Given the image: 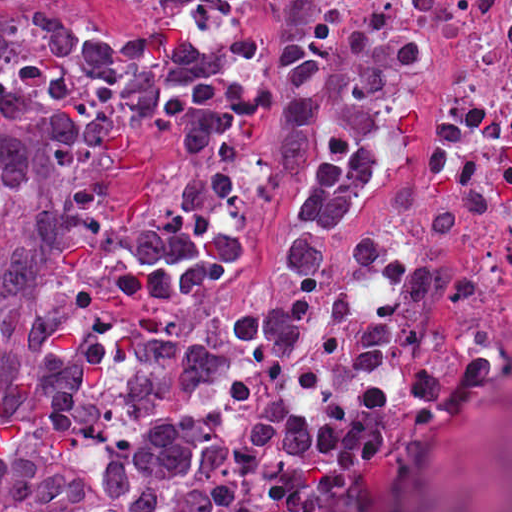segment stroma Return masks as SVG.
I'll return each mask as SVG.
<instances>
[{
  "mask_svg": "<svg viewBox=\"0 0 512 512\" xmlns=\"http://www.w3.org/2000/svg\"><path fill=\"white\" fill-rule=\"evenodd\" d=\"M43 2L94 26L169 19L197 40V63L193 78L122 111L73 168L22 178L21 201L13 213L0 217V249L137 189L140 148L148 130L171 125L211 87L203 0H0V26Z\"/></svg>",
  "mask_w": 512,
  "mask_h": 512,
  "instance_id": "35a3bbf8",
  "label": "stroma"
}]
</instances>
